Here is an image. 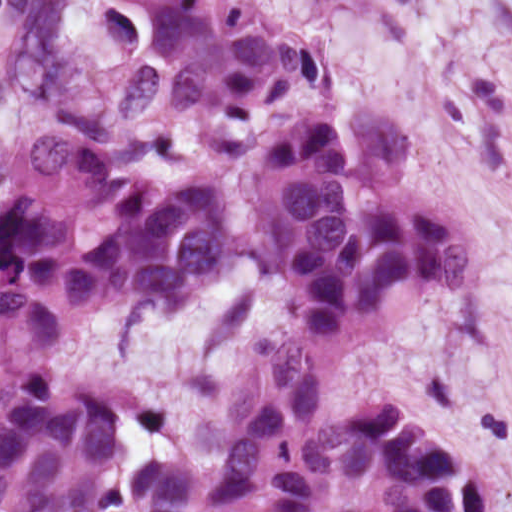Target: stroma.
I'll return each instance as SVG.
<instances>
[{"mask_svg":"<svg viewBox=\"0 0 512 512\" xmlns=\"http://www.w3.org/2000/svg\"><path fill=\"white\" fill-rule=\"evenodd\" d=\"M318 46L324 87L295 93L255 127H138L124 75L146 57V9L121 0H0V189L19 188L29 119L55 115L142 176L223 186L235 203L218 293L179 313L112 309L61 342L52 374L107 395L123 447L216 464L245 433L294 327L284 281L242 245L247 157L281 112L324 97L379 99L401 118L394 184L464 231V284L430 290L389 329L344 350L322 415L391 399L460 448L480 512H512V0H257Z\"/></svg>","mask_w":512,"mask_h":512,"instance_id":"stroma-1","label":"stroma"}]
</instances>
